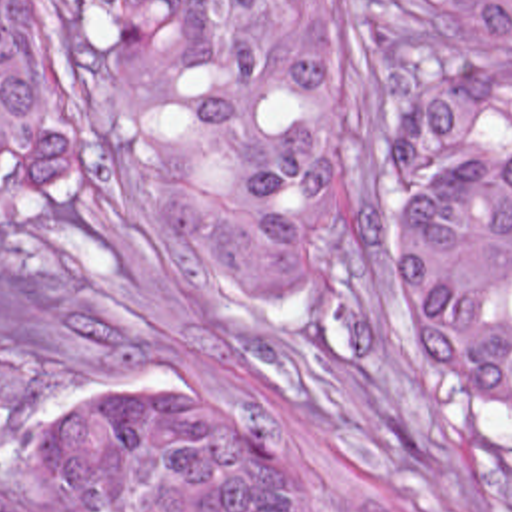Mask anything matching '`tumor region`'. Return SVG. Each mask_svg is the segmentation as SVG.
<instances>
[{
    "label": "tumor region",
    "instance_id": "obj_1",
    "mask_svg": "<svg viewBox=\"0 0 512 512\" xmlns=\"http://www.w3.org/2000/svg\"><path fill=\"white\" fill-rule=\"evenodd\" d=\"M133 108L135 162L255 313L341 293L337 0H65ZM512 52V0H418ZM414 208L413 297L446 371L512 415V54L405 100L387 126ZM57 192L19 16L0 0V218ZM45 512H315L283 443L223 395L121 377L45 433Z\"/></svg>",
    "mask_w": 512,
    "mask_h": 512
}]
</instances>
